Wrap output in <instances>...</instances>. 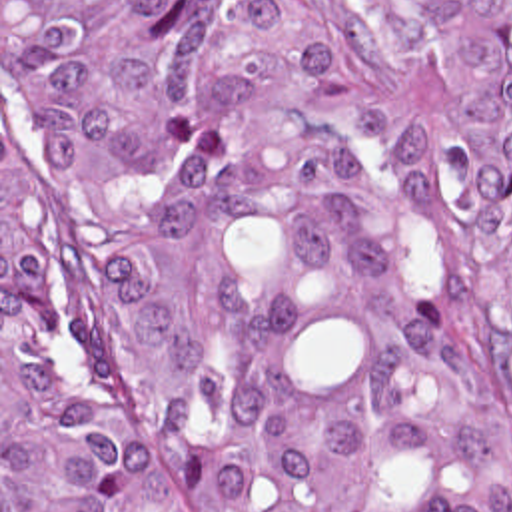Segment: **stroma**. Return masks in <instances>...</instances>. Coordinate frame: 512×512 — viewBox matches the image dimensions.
<instances>
[{"label":"stroma","instance_id":"obj_1","mask_svg":"<svg viewBox=\"0 0 512 512\" xmlns=\"http://www.w3.org/2000/svg\"><path fill=\"white\" fill-rule=\"evenodd\" d=\"M363 57V15L351 0H329ZM377 113L407 153V218L415 230V294L441 338L465 364L479 408L503 442L512 474V396L477 332L461 262L441 195V117L433 87L377 77ZM0 512H2V0H0Z\"/></svg>","mask_w":512,"mask_h":512}]
</instances>
